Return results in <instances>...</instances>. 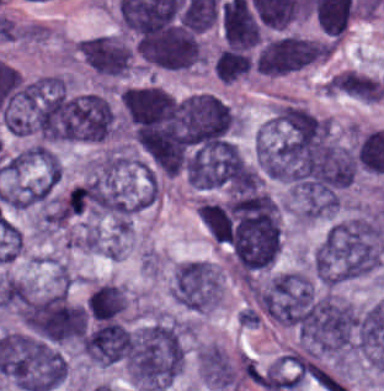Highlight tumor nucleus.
<instances>
[{
    "instance_id": "tumor-nucleus-1",
    "label": "tumor nucleus",
    "mask_w": 384,
    "mask_h": 391,
    "mask_svg": "<svg viewBox=\"0 0 384 391\" xmlns=\"http://www.w3.org/2000/svg\"><path fill=\"white\" fill-rule=\"evenodd\" d=\"M189 324L184 317L155 311L131 326L125 368L133 391H164L180 373Z\"/></svg>"
},
{
    "instance_id": "tumor-nucleus-2",
    "label": "tumor nucleus",
    "mask_w": 384,
    "mask_h": 391,
    "mask_svg": "<svg viewBox=\"0 0 384 391\" xmlns=\"http://www.w3.org/2000/svg\"><path fill=\"white\" fill-rule=\"evenodd\" d=\"M384 259V227L374 214L359 210L333 223L314 255L318 281L337 285L370 275Z\"/></svg>"
},
{
    "instance_id": "tumor-nucleus-3",
    "label": "tumor nucleus",
    "mask_w": 384,
    "mask_h": 391,
    "mask_svg": "<svg viewBox=\"0 0 384 391\" xmlns=\"http://www.w3.org/2000/svg\"><path fill=\"white\" fill-rule=\"evenodd\" d=\"M15 313L33 337L58 346H76L78 308L65 289L33 285Z\"/></svg>"
},
{
    "instance_id": "tumor-nucleus-4",
    "label": "tumor nucleus",
    "mask_w": 384,
    "mask_h": 391,
    "mask_svg": "<svg viewBox=\"0 0 384 391\" xmlns=\"http://www.w3.org/2000/svg\"><path fill=\"white\" fill-rule=\"evenodd\" d=\"M220 291L221 278L216 264L190 259L173 268L169 293L183 306L208 310L218 304Z\"/></svg>"
},
{
    "instance_id": "tumor-nucleus-5",
    "label": "tumor nucleus",
    "mask_w": 384,
    "mask_h": 391,
    "mask_svg": "<svg viewBox=\"0 0 384 391\" xmlns=\"http://www.w3.org/2000/svg\"><path fill=\"white\" fill-rule=\"evenodd\" d=\"M328 52V41L284 35L260 47L258 68L269 75L295 72L327 58Z\"/></svg>"
},
{
    "instance_id": "tumor-nucleus-6",
    "label": "tumor nucleus",
    "mask_w": 384,
    "mask_h": 391,
    "mask_svg": "<svg viewBox=\"0 0 384 391\" xmlns=\"http://www.w3.org/2000/svg\"><path fill=\"white\" fill-rule=\"evenodd\" d=\"M74 49L100 75L122 77L131 69L132 49L123 37L99 35L80 40Z\"/></svg>"
},
{
    "instance_id": "tumor-nucleus-7",
    "label": "tumor nucleus",
    "mask_w": 384,
    "mask_h": 391,
    "mask_svg": "<svg viewBox=\"0 0 384 391\" xmlns=\"http://www.w3.org/2000/svg\"><path fill=\"white\" fill-rule=\"evenodd\" d=\"M197 210L209 237L216 243L227 247L233 224L229 208L221 201L201 199L197 203Z\"/></svg>"
},
{
    "instance_id": "tumor-nucleus-8",
    "label": "tumor nucleus",
    "mask_w": 384,
    "mask_h": 391,
    "mask_svg": "<svg viewBox=\"0 0 384 391\" xmlns=\"http://www.w3.org/2000/svg\"><path fill=\"white\" fill-rule=\"evenodd\" d=\"M87 308L94 318L108 320L123 311L127 305V293L124 285L104 283L90 294Z\"/></svg>"
},
{
    "instance_id": "tumor-nucleus-9",
    "label": "tumor nucleus",
    "mask_w": 384,
    "mask_h": 391,
    "mask_svg": "<svg viewBox=\"0 0 384 391\" xmlns=\"http://www.w3.org/2000/svg\"><path fill=\"white\" fill-rule=\"evenodd\" d=\"M326 94H330V95H334V96H337V97H341V98H345V99H349V100H352V101H356V102H360V103H370L330 82L327 81V85H326ZM372 104V103H370Z\"/></svg>"
}]
</instances>
